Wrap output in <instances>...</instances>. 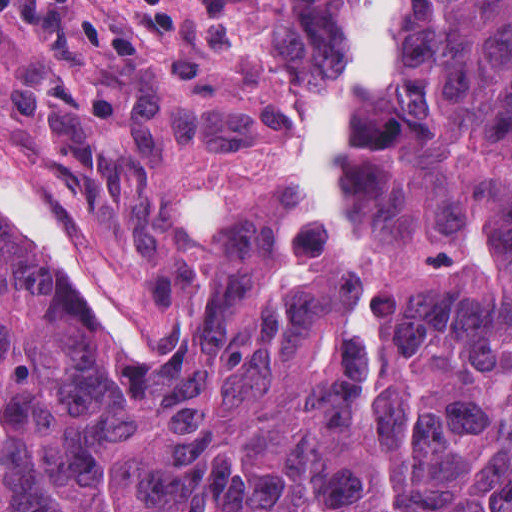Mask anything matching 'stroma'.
Returning <instances> with one entry per match:
<instances>
[{
    "mask_svg": "<svg viewBox=\"0 0 512 512\" xmlns=\"http://www.w3.org/2000/svg\"><path fill=\"white\" fill-rule=\"evenodd\" d=\"M424 2H393L400 54ZM364 6L0 0V183L18 201H53L121 271L132 341L153 364L298 188L291 157L329 104Z\"/></svg>",
    "mask_w": 512,
    "mask_h": 512,
    "instance_id": "1",
    "label": "stroma"
}]
</instances>
